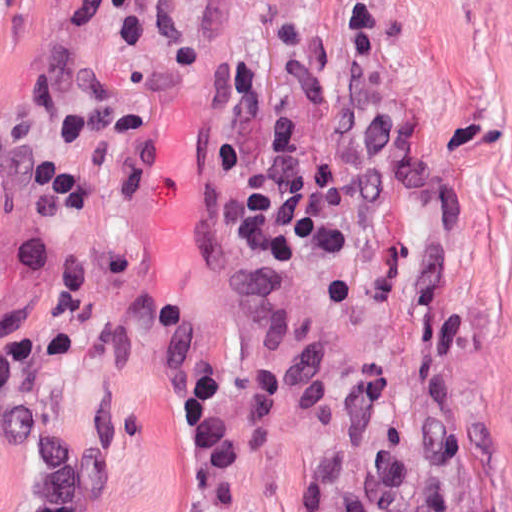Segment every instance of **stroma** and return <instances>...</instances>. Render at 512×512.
Wrapping results in <instances>:
<instances>
[{"instance_id": "stroma-1", "label": "stroma", "mask_w": 512, "mask_h": 512, "mask_svg": "<svg viewBox=\"0 0 512 512\" xmlns=\"http://www.w3.org/2000/svg\"><path fill=\"white\" fill-rule=\"evenodd\" d=\"M184 2L189 65L145 72L0 0V316L31 325L19 372L87 452L88 512L181 511L174 386L211 351L240 444L223 512H512V0ZM233 65L253 158L273 116L316 156L341 105L391 109L393 202L349 258L267 279L228 233L205 143ZM49 162L94 193L58 233L135 363L48 348L60 291L18 247ZM36 490L0 438V512Z\"/></svg>"}]
</instances>
